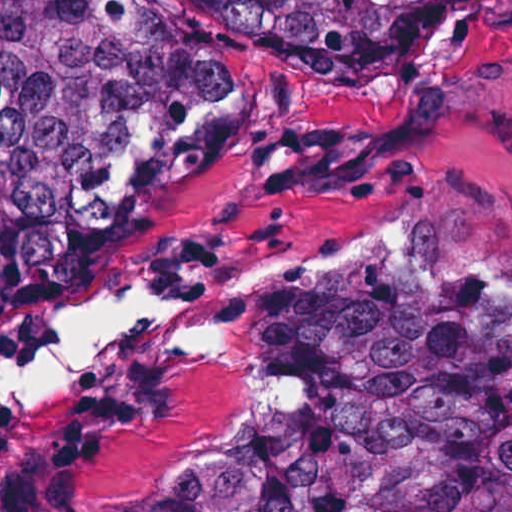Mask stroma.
I'll return each mask as SVG.
<instances>
[{"label": "stroma", "instance_id": "1", "mask_svg": "<svg viewBox=\"0 0 512 512\" xmlns=\"http://www.w3.org/2000/svg\"><path fill=\"white\" fill-rule=\"evenodd\" d=\"M151 1L190 52L241 82L242 119L224 154L98 237L69 305L36 326L0 325V372L37 360L63 312L99 287L182 304L334 253L379 221L412 223L431 256L512 296V0L461 14L388 71L282 50L199 0ZM390 257L248 291L225 307V333L249 350V309L264 298L360 285ZM246 398L219 359L140 335L57 390L0 400V512H150L186 467L292 409L184 446Z\"/></svg>", "mask_w": 512, "mask_h": 512}]
</instances>
